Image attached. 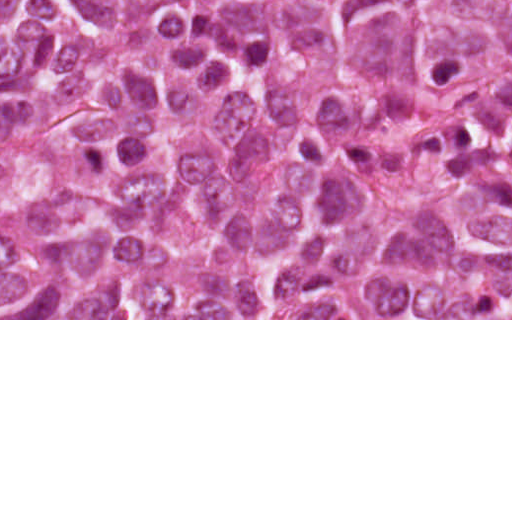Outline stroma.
I'll list each match as a JSON object with an SVG mask.
<instances>
[{
  "label": "stroma",
  "instance_id": "stroma-1",
  "mask_svg": "<svg viewBox=\"0 0 512 512\" xmlns=\"http://www.w3.org/2000/svg\"><path fill=\"white\" fill-rule=\"evenodd\" d=\"M0 320H512V319H129V318H1V0H0Z\"/></svg>",
  "mask_w": 512,
  "mask_h": 512
}]
</instances>
